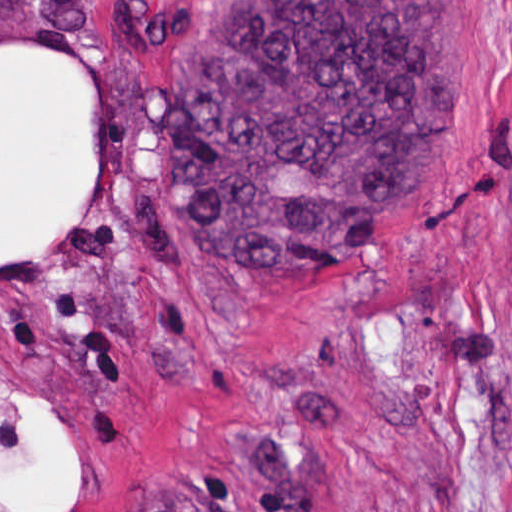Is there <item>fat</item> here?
<instances>
[{
	"label": "fat",
	"mask_w": 512,
	"mask_h": 512,
	"mask_svg": "<svg viewBox=\"0 0 512 512\" xmlns=\"http://www.w3.org/2000/svg\"><path fill=\"white\" fill-rule=\"evenodd\" d=\"M99 157V78L73 48L1 45V259L84 209ZM23 434L1 460V509L74 512L76 447L40 396L22 399Z\"/></svg>",
	"instance_id": "fat-1"
}]
</instances>
